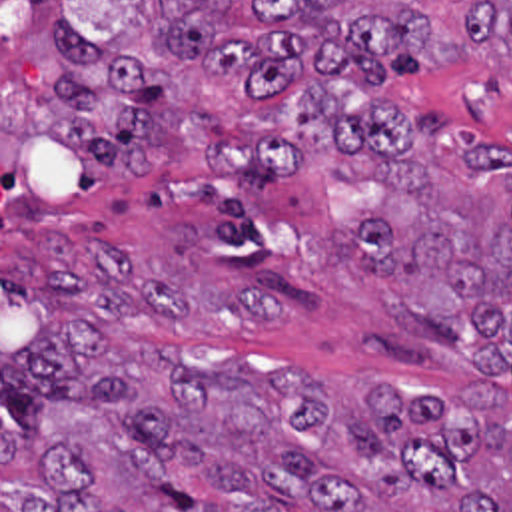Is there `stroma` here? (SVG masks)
I'll list each match as a JSON object with an SVG mask.
<instances>
[{"label":"stroma","mask_w":512,"mask_h":512,"mask_svg":"<svg viewBox=\"0 0 512 512\" xmlns=\"http://www.w3.org/2000/svg\"><path fill=\"white\" fill-rule=\"evenodd\" d=\"M150 0H0V267L36 263L112 279L140 302L156 348L184 368L230 374L307 372L341 416L371 382L397 396H433L481 382L512 414V376L477 368L441 334L401 318L347 259L355 227L387 195L373 163L315 155L276 187H230L198 161H168L140 183L92 171L46 129L58 107L48 27L72 21L104 51L158 67L180 97L214 119L234 115L244 85L210 83L162 57L144 11ZM483 1L345 0L405 7L453 33L463 61L387 85L311 75L256 107H290L319 81L367 101L469 131L512 157V45L467 41L461 9ZM218 37L262 33L252 0L212 15Z\"/></svg>","instance_id":"1"}]
</instances>
